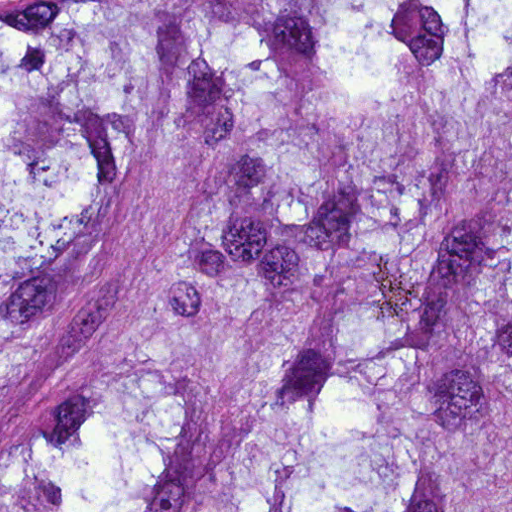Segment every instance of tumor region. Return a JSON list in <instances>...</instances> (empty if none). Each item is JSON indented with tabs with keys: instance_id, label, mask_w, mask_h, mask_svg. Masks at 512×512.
I'll return each mask as SVG.
<instances>
[{
	"instance_id": "obj_1",
	"label": "tumor region",
	"mask_w": 512,
	"mask_h": 512,
	"mask_svg": "<svg viewBox=\"0 0 512 512\" xmlns=\"http://www.w3.org/2000/svg\"><path fill=\"white\" fill-rule=\"evenodd\" d=\"M0 512H512V0H0Z\"/></svg>"
}]
</instances>
